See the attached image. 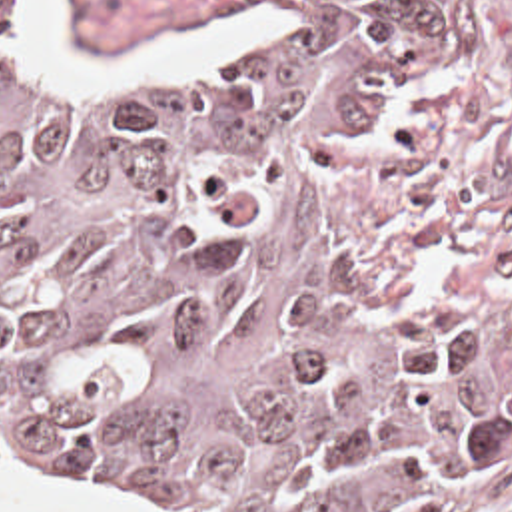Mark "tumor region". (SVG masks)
Here are the masks:
<instances>
[{
    "instance_id": "e687c5a6",
    "label": "tumor region",
    "mask_w": 512,
    "mask_h": 512,
    "mask_svg": "<svg viewBox=\"0 0 512 512\" xmlns=\"http://www.w3.org/2000/svg\"><path fill=\"white\" fill-rule=\"evenodd\" d=\"M436 0H276L268 47L49 89L0 0V446L176 512H416L504 422L352 257Z\"/></svg>"
}]
</instances>
